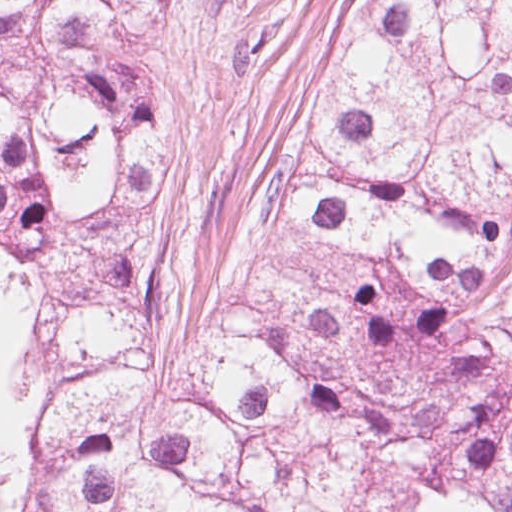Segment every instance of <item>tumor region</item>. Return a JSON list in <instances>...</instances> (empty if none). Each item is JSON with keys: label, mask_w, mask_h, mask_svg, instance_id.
<instances>
[{"label": "tumor region", "mask_w": 512, "mask_h": 512, "mask_svg": "<svg viewBox=\"0 0 512 512\" xmlns=\"http://www.w3.org/2000/svg\"><path fill=\"white\" fill-rule=\"evenodd\" d=\"M5 512H219L17 446V492Z\"/></svg>", "instance_id": "obj_1"}]
</instances>
